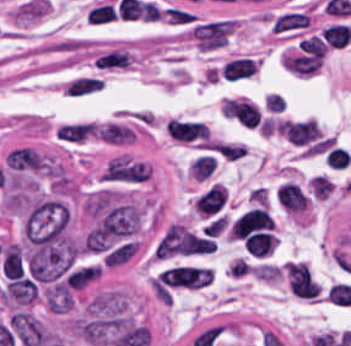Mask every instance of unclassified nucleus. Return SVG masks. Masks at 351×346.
<instances>
[{"label": "unclassified nucleus", "instance_id": "obj_1", "mask_svg": "<svg viewBox=\"0 0 351 346\" xmlns=\"http://www.w3.org/2000/svg\"><path fill=\"white\" fill-rule=\"evenodd\" d=\"M37 294L35 284L27 277H13L3 288L2 300L16 305L32 302Z\"/></svg>", "mask_w": 351, "mask_h": 346}]
</instances>
